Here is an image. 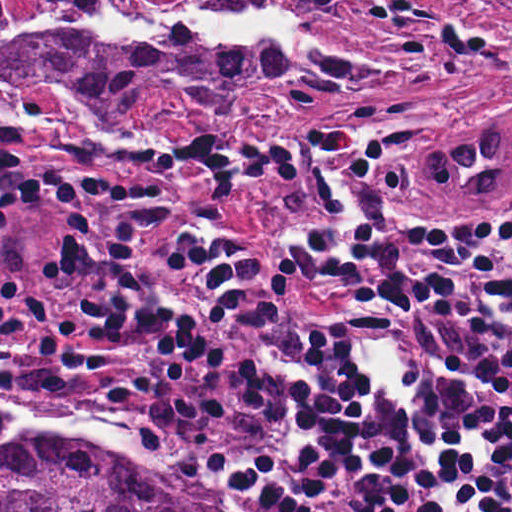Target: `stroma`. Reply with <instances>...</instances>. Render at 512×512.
I'll use <instances>...</instances> for the list:
<instances>
[{
  "instance_id": "obj_1",
  "label": "stroma",
  "mask_w": 512,
  "mask_h": 512,
  "mask_svg": "<svg viewBox=\"0 0 512 512\" xmlns=\"http://www.w3.org/2000/svg\"><path fill=\"white\" fill-rule=\"evenodd\" d=\"M146 1L187 8L206 0ZM313 30L322 41L395 71L320 90L247 119H194L182 109L102 112L52 74L16 81L10 96L1 99L0 0V512L1 440L53 431L87 433L113 444L184 490L194 512H212L166 447L145 440L138 430L1 398V118L20 114L16 136L24 176L36 195L29 207L12 212L8 225L18 239L28 283L62 322L73 320L76 310L59 259L60 211L43 178L50 168L101 174L132 188L166 192L171 214L143 234L137 251L139 278L164 305L189 313L205 304L200 277L178 269L170 251L182 235L208 224L252 241L270 273L291 286L294 310L319 314L348 308L342 295L282 264L285 235L315 214L316 199L291 185L243 188L229 198L211 197L204 172L185 164V145L197 125L220 141L250 151L302 132L354 129L373 155L394 168L434 213L512 232V204L484 218L441 200L423 182L400 171L433 160L436 144L453 121L512 106V0H383L371 8L322 10ZM77 114H101L91 123L97 138L155 146L165 161L122 165L74 157L67 145L82 130ZM1 408L12 418L5 429Z\"/></svg>"
}]
</instances>
